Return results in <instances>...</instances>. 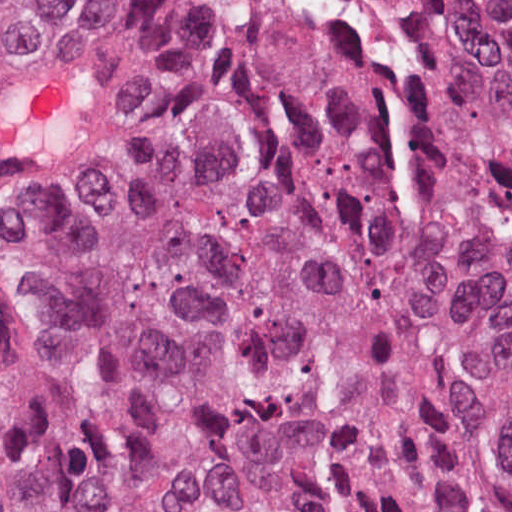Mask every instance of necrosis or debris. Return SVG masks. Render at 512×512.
I'll list each match as a JSON object with an SVG mask.
<instances>
[{
    "instance_id": "1",
    "label": "necrosis or debris",
    "mask_w": 512,
    "mask_h": 512,
    "mask_svg": "<svg viewBox=\"0 0 512 512\" xmlns=\"http://www.w3.org/2000/svg\"><path fill=\"white\" fill-rule=\"evenodd\" d=\"M463 38L484 47L500 66L512 101V0H428Z\"/></svg>"
}]
</instances>
